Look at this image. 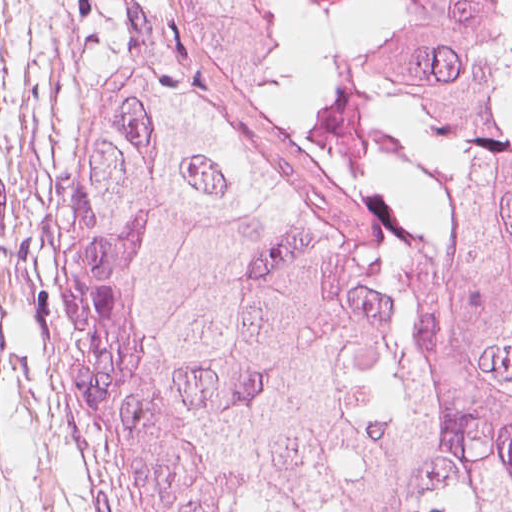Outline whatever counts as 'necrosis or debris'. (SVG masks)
<instances>
[{"instance_id":"1","label":"necrosis or debris","mask_w":512,"mask_h":512,"mask_svg":"<svg viewBox=\"0 0 512 512\" xmlns=\"http://www.w3.org/2000/svg\"><path fill=\"white\" fill-rule=\"evenodd\" d=\"M308 71L384 130L493 95L512 115V0H282Z\"/></svg>"}]
</instances>
